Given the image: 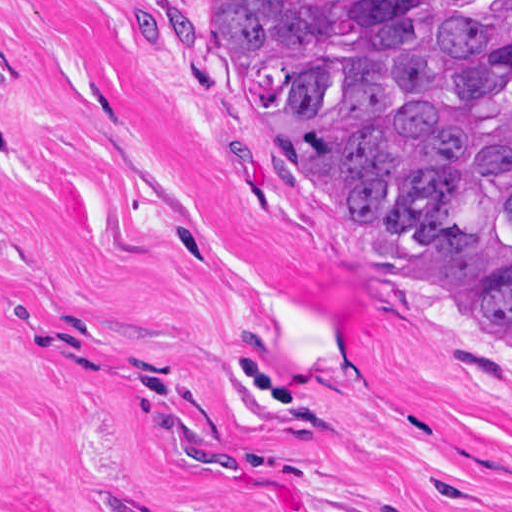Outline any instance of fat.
<instances>
[{"instance_id": "1", "label": "fat", "mask_w": 512, "mask_h": 512, "mask_svg": "<svg viewBox=\"0 0 512 512\" xmlns=\"http://www.w3.org/2000/svg\"><path fill=\"white\" fill-rule=\"evenodd\" d=\"M367 512H432L399 498L368 510Z\"/></svg>"}]
</instances>
